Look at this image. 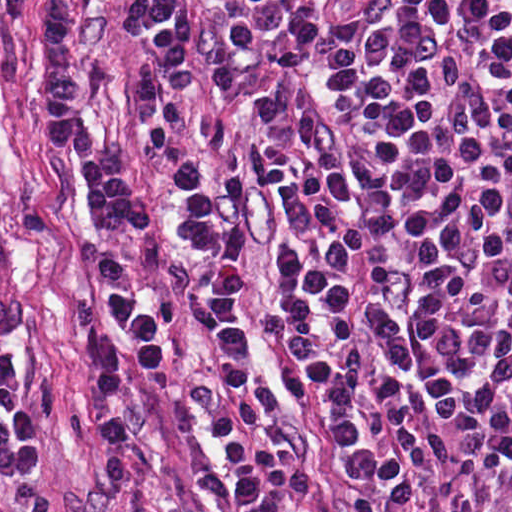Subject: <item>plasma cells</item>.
Wrapping results in <instances>:
<instances>
[{"instance_id": "obj_1", "label": "plasma cells", "mask_w": 512, "mask_h": 512, "mask_svg": "<svg viewBox=\"0 0 512 512\" xmlns=\"http://www.w3.org/2000/svg\"><path fill=\"white\" fill-rule=\"evenodd\" d=\"M265 65L242 178L285 245L261 301L329 442L397 512H512V0H227ZM140 362L165 329L111 287ZM39 454L0 394V478Z\"/></svg>"}]
</instances>
